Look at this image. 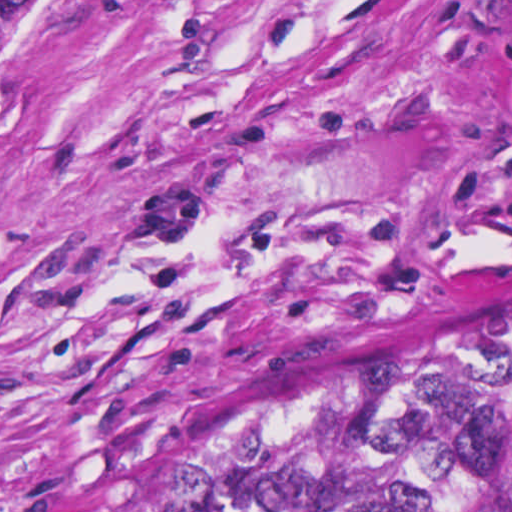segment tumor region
I'll list each match as a JSON object with an SVG mask.
<instances>
[{
    "instance_id": "1",
    "label": "tumor region",
    "mask_w": 512,
    "mask_h": 512,
    "mask_svg": "<svg viewBox=\"0 0 512 512\" xmlns=\"http://www.w3.org/2000/svg\"><path fill=\"white\" fill-rule=\"evenodd\" d=\"M99 0H0V122ZM64 512H512V264L325 335Z\"/></svg>"
}]
</instances>
